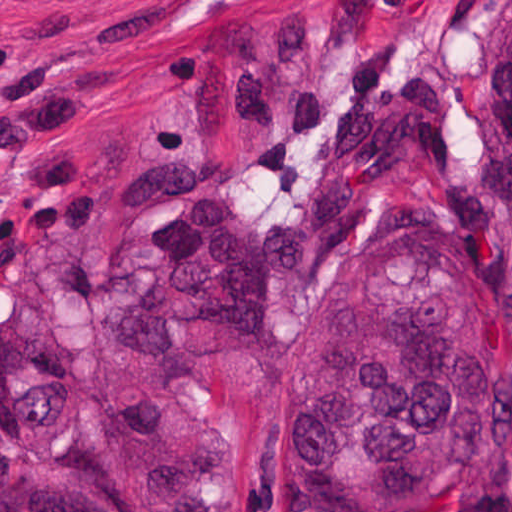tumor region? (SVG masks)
Returning a JSON list of instances; mask_svg holds the SVG:
<instances>
[{"instance_id":"obj_1","label":"tumor region","mask_w":512,"mask_h":512,"mask_svg":"<svg viewBox=\"0 0 512 512\" xmlns=\"http://www.w3.org/2000/svg\"><path fill=\"white\" fill-rule=\"evenodd\" d=\"M477 72L497 211L473 182L447 213L399 226L293 344V512H435L484 461L512 463V0L483 20ZM150 196L166 206L139 237L149 280L108 303L124 352H173L180 325L263 343L280 282L359 237L340 178L311 187L280 227L209 192L195 154L140 160L126 201ZM11 414L30 460L75 476L2 490L0 512H209L187 462H108L51 382L18 386Z\"/></svg>"}]
</instances>
